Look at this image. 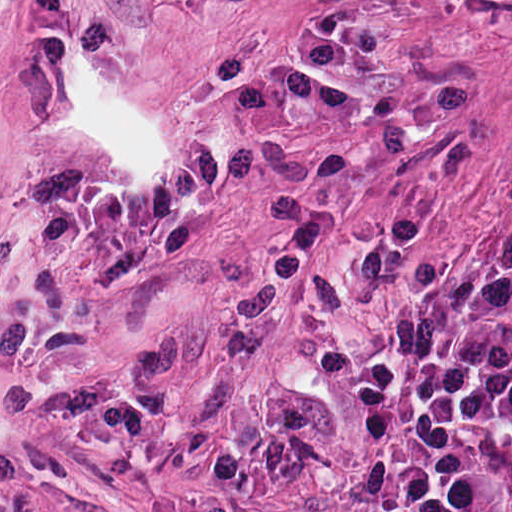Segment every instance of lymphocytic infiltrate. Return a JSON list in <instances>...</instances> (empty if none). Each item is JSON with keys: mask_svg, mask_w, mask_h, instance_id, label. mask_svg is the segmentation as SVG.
<instances>
[{"mask_svg": "<svg viewBox=\"0 0 512 512\" xmlns=\"http://www.w3.org/2000/svg\"><path fill=\"white\" fill-rule=\"evenodd\" d=\"M400 512H512V247L415 310Z\"/></svg>", "mask_w": 512, "mask_h": 512, "instance_id": "obj_1", "label": "lymphocytic infiltrate"}]
</instances>
